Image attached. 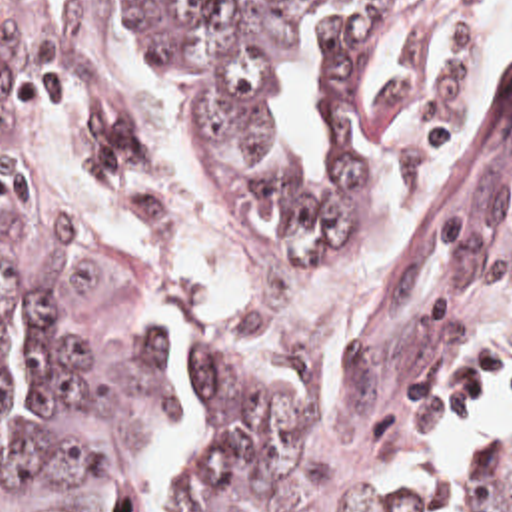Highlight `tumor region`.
<instances>
[{"mask_svg": "<svg viewBox=\"0 0 512 512\" xmlns=\"http://www.w3.org/2000/svg\"><path fill=\"white\" fill-rule=\"evenodd\" d=\"M115 1L191 112L215 212L253 282L189 358L183 512H425V490L385 502L375 484L415 420L461 412L512 350V74L457 152L407 266L355 288L339 268L349 224L445 118L479 30L393 94L413 0ZM317 10H329L333 190L305 178L267 114L287 30ZM45 18L41 0H0V406L8 320L23 332V430L0 450V512H121V466L167 422L173 330L125 318L89 330L65 308L63 264L129 186L141 136L125 100H91L87 200L63 214L31 196L14 148L59 92ZM469 506L512 512V446L485 442Z\"/></svg>", "mask_w": 512, "mask_h": 512, "instance_id": "tumor-region-1", "label": "tumor region"}]
</instances>
